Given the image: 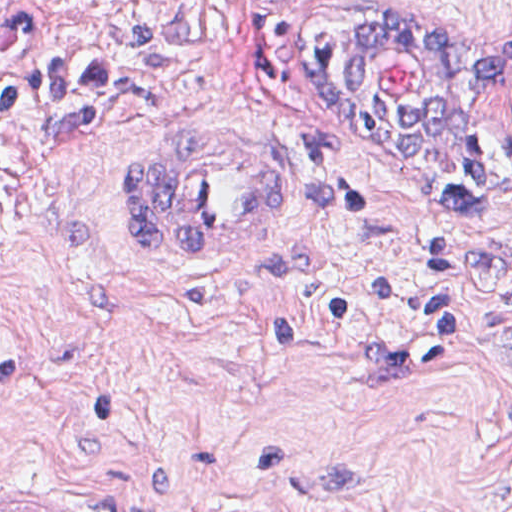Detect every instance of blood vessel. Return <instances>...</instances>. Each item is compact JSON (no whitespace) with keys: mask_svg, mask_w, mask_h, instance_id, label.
<instances>
[{"mask_svg":"<svg viewBox=\"0 0 512 512\" xmlns=\"http://www.w3.org/2000/svg\"><path fill=\"white\" fill-rule=\"evenodd\" d=\"M384 0H234L248 26L307 28ZM120 194L128 240L162 258H243L279 230L287 185L261 164L219 143H195L127 164ZM0 512H68L40 500Z\"/></svg>","mask_w":512,"mask_h":512,"instance_id":"1","label":"blood vessel"}]
</instances>
